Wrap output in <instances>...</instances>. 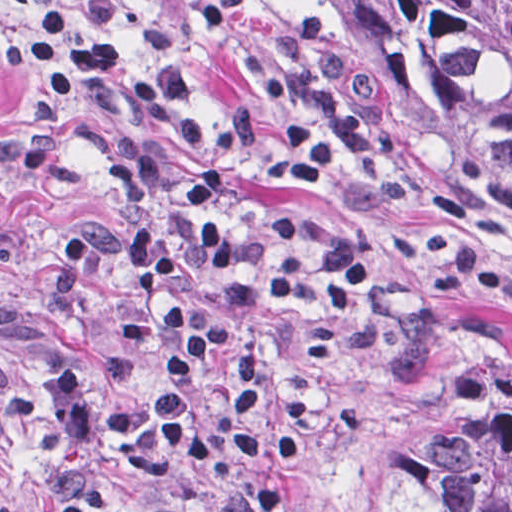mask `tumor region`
Masks as SVG:
<instances>
[{"label":"tumor region","mask_w":512,"mask_h":512,"mask_svg":"<svg viewBox=\"0 0 512 512\" xmlns=\"http://www.w3.org/2000/svg\"><path fill=\"white\" fill-rule=\"evenodd\" d=\"M326 7L405 139L512 228V0H293ZM405 512H512V376L446 398L408 443Z\"/></svg>","instance_id":"tumor-region-1"}]
</instances>
